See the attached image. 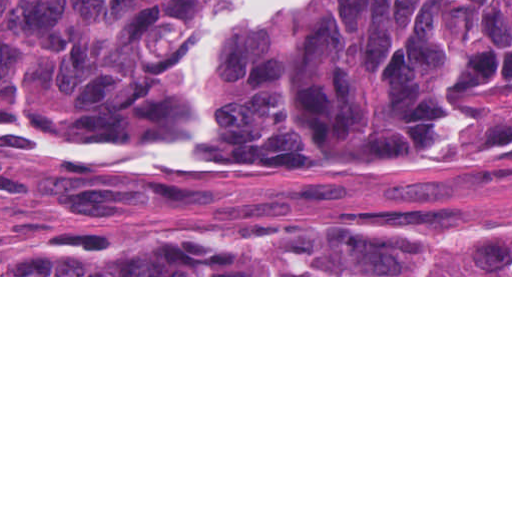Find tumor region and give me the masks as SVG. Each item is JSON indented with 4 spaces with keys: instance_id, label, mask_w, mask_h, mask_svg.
Instances as JSON below:
<instances>
[{
    "instance_id": "obj_1",
    "label": "tumor region",
    "mask_w": 512,
    "mask_h": 512,
    "mask_svg": "<svg viewBox=\"0 0 512 512\" xmlns=\"http://www.w3.org/2000/svg\"><path fill=\"white\" fill-rule=\"evenodd\" d=\"M213 1L0 0V131L134 190L178 188L238 145L416 185L512 167V0H315L235 42L213 147L162 170L110 164L181 125ZM0 275H512V226L248 219L84 237Z\"/></svg>"
}]
</instances>
